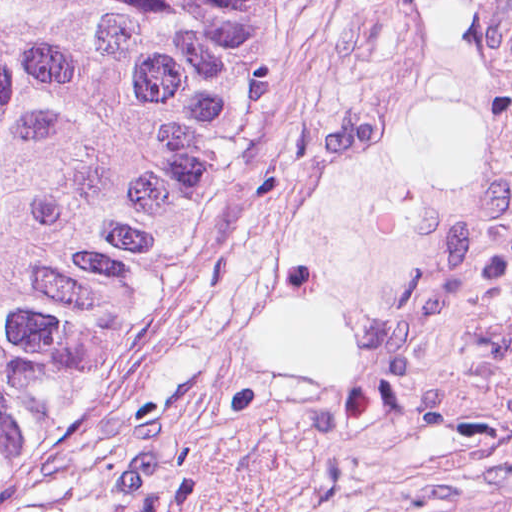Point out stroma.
Listing matches in <instances>:
<instances>
[{
    "label": "stroma",
    "instance_id": "obj_1",
    "mask_svg": "<svg viewBox=\"0 0 512 512\" xmlns=\"http://www.w3.org/2000/svg\"><path fill=\"white\" fill-rule=\"evenodd\" d=\"M418 0H286L109 375L22 512L512 508V45L500 140L388 366L258 346L282 279L423 81Z\"/></svg>",
    "mask_w": 512,
    "mask_h": 512
}]
</instances>
